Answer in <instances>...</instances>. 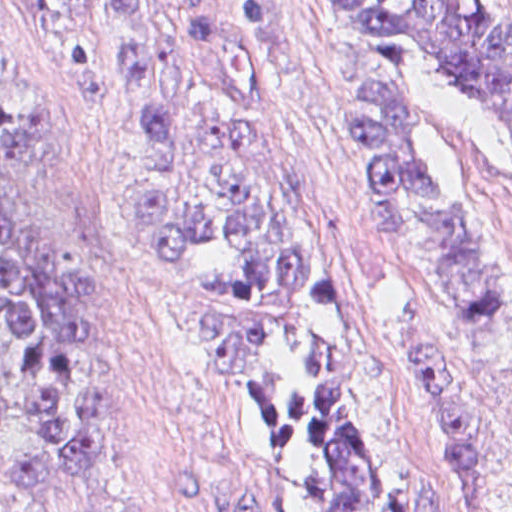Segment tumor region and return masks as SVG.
I'll list each match as a JSON object with an SVG mask.
<instances>
[{
	"label": "tumor region",
	"instance_id": "1",
	"mask_svg": "<svg viewBox=\"0 0 512 512\" xmlns=\"http://www.w3.org/2000/svg\"><path fill=\"white\" fill-rule=\"evenodd\" d=\"M25 1L37 36L126 86L136 201L245 371L291 511L381 512L382 386L332 293L265 5ZM318 5L350 82L375 237L451 313L495 322L493 274L410 156L406 91L439 58L494 91L512 121V54L471 0ZM50 115L51 92L0 24V491L89 506L115 455L125 337L100 249L23 178ZM177 485L194 512H263L254 491L199 471Z\"/></svg>",
	"mask_w": 512,
	"mask_h": 512
}]
</instances>
